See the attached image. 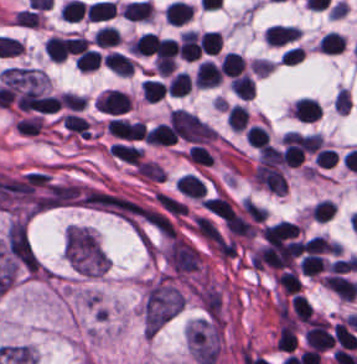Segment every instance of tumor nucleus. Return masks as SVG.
I'll return each instance as SVG.
<instances>
[{"label": "tumor nucleus", "instance_id": "obj_2", "mask_svg": "<svg viewBox=\"0 0 357 364\" xmlns=\"http://www.w3.org/2000/svg\"><path fill=\"white\" fill-rule=\"evenodd\" d=\"M190 350L200 364H213L219 353L218 322L197 321L188 329Z\"/></svg>", "mask_w": 357, "mask_h": 364}, {"label": "tumor nucleus", "instance_id": "obj_1", "mask_svg": "<svg viewBox=\"0 0 357 364\" xmlns=\"http://www.w3.org/2000/svg\"><path fill=\"white\" fill-rule=\"evenodd\" d=\"M182 307V298L173 283L161 280L144 298V335L156 333Z\"/></svg>", "mask_w": 357, "mask_h": 364}, {"label": "tumor nucleus", "instance_id": "obj_3", "mask_svg": "<svg viewBox=\"0 0 357 364\" xmlns=\"http://www.w3.org/2000/svg\"><path fill=\"white\" fill-rule=\"evenodd\" d=\"M6 256L17 266L34 272L37 268L36 255L22 220H15L9 227L5 239Z\"/></svg>", "mask_w": 357, "mask_h": 364}]
</instances>
